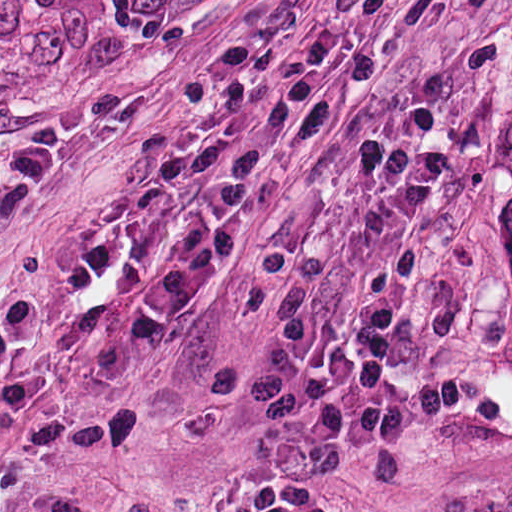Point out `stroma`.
Segmentation results:
<instances>
[{
  "mask_svg": "<svg viewBox=\"0 0 512 512\" xmlns=\"http://www.w3.org/2000/svg\"><path fill=\"white\" fill-rule=\"evenodd\" d=\"M402 114L448 196L402 289L429 399L340 467L344 512L512 484V262L476 170L512 127V0H0V512H217L280 416L272 358L365 266L333 170Z\"/></svg>",
  "mask_w": 512,
  "mask_h": 512,
  "instance_id": "35a3bbf8",
  "label": "stroma"
}]
</instances>
